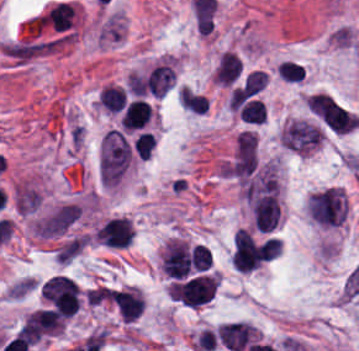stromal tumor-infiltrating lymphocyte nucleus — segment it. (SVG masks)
<instances>
[{"label": "stromal tumor-infiltrating lymphocyte nucleus", "instance_id": "bc302bb0", "mask_svg": "<svg viewBox=\"0 0 359 351\" xmlns=\"http://www.w3.org/2000/svg\"><path fill=\"white\" fill-rule=\"evenodd\" d=\"M218 274H199L169 285V296L182 306L197 308L208 303L214 295Z\"/></svg>", "mask_w": 359, "mask_h": 351}, {"label": "stromal tumor-infiltrating lymphocyte nucleus", "instance_id": "3290ff9b", "mask_svg": "<svg viewBox=\"0 0 359 351\" xmlns=\"http://www.w3.org/2000/svg\"><path fill=\"white\" fill-rule=\"evenodd\" d=\"M160 265L166 276L183 279L188 275L191 264L187 242L172 237L166 240L160 256Z\"/></svg>", "mask_w": 359, "mask_h": 351}, {"label": "stromal tumor-infiltrating lymphocyte nucleus", "instance_id": "4f13568d", "mask_svg": "<svg viewBox=\"0 0 359 351\" xmlns=\"http://www.w3.org/2000/svg\"><path fill=\"white\" fill-rule=\"evenodd\" d=\"M276 74L285 82H299L304 75V68L297 62L284 60L277 68Z\"/></svg>", "mask_w": 359, "mask_h": 351}, {"label": "stromal tumor-infiltrating lymphocyte nucleus", "instance_id": "abfb95fc", "mask_svg": "<svg viewBox=\"0 0 359 351\" xmlns=\"http://www.w3.org/2000/svg\"><path fill=\"white\" fill-rule=\"evenodd\" d=\"M241 70L240 60L237 55L222 52L213 71V79L216 84L229 85L239 75Z\"/></svg>", "mask_w": 359, "mask_h": 351}, {"label": "stromal tumor-infiltrating lymphocyte nucleus", "instance_id": "4803ca6d", "mask_svg": "<svg viewBox=\"0 0 359 351\" xmlns=\"http://www.w3.org/2000/svg\"><path fill=\"white\" fill-rule=\"evenodd\" d=\"M154 141L146 131H139L132 141V148L139 159H146L151 152Z\"/></svg>", "mask_w": 359, "mask_h": 351}, {"label": "stromal tumor-infiltrating lymphocyte nucleus", "instance_id": "f3e2335f", "mask_svg": "<svg viewBox=\"0 0 359 351\" xmlns=\"http://www.w3.org/2000/svg\"><path fill=\"white\" fill-rule=\"evenodd\" d=\"M96 101L106 111H116L124 104L123 88L111 84H104L96 94Z\"/></svg>", "mask_w": 359, "mask_h": 351}, {"label": "stromal tumor-infiltrating lymphocyte nucleus", "instance_id": "4245b91a", "mask_svg": "<svg viewBox=\"0 0 359 351\" xmlns=\"http://www.w3.org/2000/svg\"><path fill=\"white\" fill-rule=\"evenodd\" d=\"M265 117V104L253 99L240 120H244L250 123H262Z\"/></svg>", "mask_w": 359, "mask_h": 351}, {"label": "stromal tumor-infiltrating lymphocyte nucleus", "instance_id": "2a367800", "mask_svg": "<svg viewBox=\"0 0 359 351\" xmlns=\"http://www.w3.org/2000/svg\"><path fill=\"white\" fill-rule=\"evenodd\" d=\"M211 262V253L206 247L195 244L190 251V265L194 270L203 271Z\"/></svg>", "mask_w": 359, "mask_h": 351}, {"label": "stromal tumor-infiltrating lymphocyte nucleus", "instance_id": "9ea309e8", "mask_svg": "<svg viewBox=\"0 0 359 351\" xmlns=\"http://www.w3.org/2000/svg\"><path fill=\"white\" fill-rule=\"evenodd\" d=\"M149 114V104L140 99H133L127 103L121 115L120 123L127 130H134L143 127Z\"/></svg>", "mask_w": 359, "mask_h": 351}, {"label": "stromal tumor-infiltrating lymphocyte nucleus", "instance_id": "52c7bb5b", "mask_svg": "<svg viewBox=\"0 0 359 351\" xmlns=\"http://www.w3.org/2000/svg\"><path fill=\"white\" fill-rule=\"evenodd\" d=\"M41 294L45 303L57 315L67 318L77 311L80 292L70 278L53 275L44 283Z\"/></svg>", "mask_w": 359, "mask_h": 351}]
</instances>
